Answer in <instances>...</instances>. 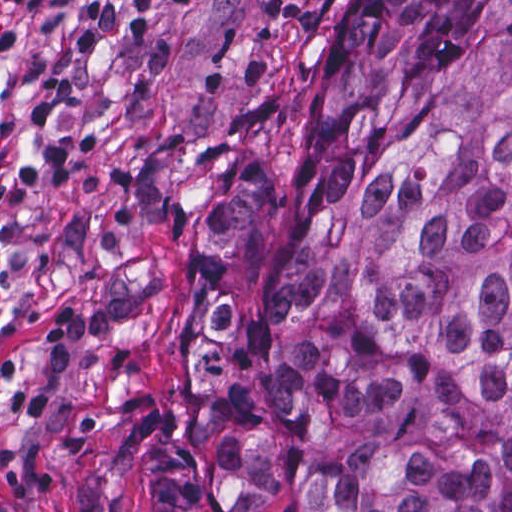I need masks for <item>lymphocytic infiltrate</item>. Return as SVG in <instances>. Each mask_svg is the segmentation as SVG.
<instances>
[{"label": "lymphocytic infiltrate", "instance_id": "lymphocytic-infiltrate-1", "mask_svg": "<svg viewBox=\"0 0 512 512\" xmlns=\"http://www.w3.org/2000/svg\"><path fill=\"white\" fill-rule=\"evenodd\" d=\"M54 0H0V10L11 6H46ZM299 0H264L265 10L271 22L284 23L287 15ZM14 23L0 16V52L9 49L19 38Z\"/></svg>", "mask_w": 512, "mask_h": 512}]
</instances>
